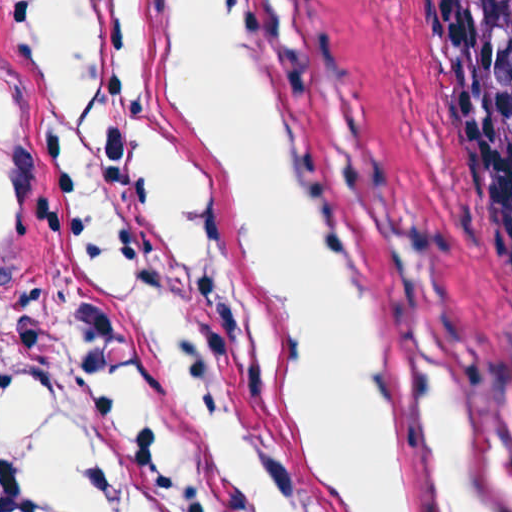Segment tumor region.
<instances>
[{
	"label": "tumor region",
	"instance_id": "tumor-region-1",
	"mask_svg": "<svg viewBox=\"0 0 512 512\" xmlns=\"http://www.w3.org/2000/svg\"><path fill=\"white\" fill-rule=\"evenodd\" d=\"M512 129V0H459Z\"/></svg>",
	"mask_w": 512,
	"mask_h": 512
}]
</instances>
